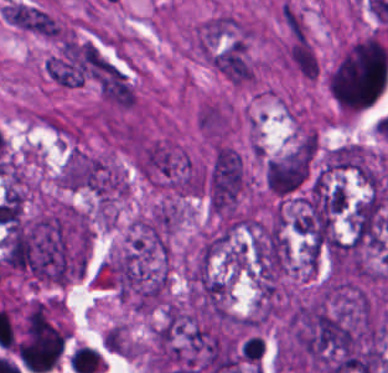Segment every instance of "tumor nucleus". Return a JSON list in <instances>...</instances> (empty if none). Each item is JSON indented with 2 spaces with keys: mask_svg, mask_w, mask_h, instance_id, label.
<instances>
[{
  "mask_svg": "<svg viewBox=\"0 0 388 373\" xmlns=\"http://www.w3.org/2000/svg\"><path fill=\"white\" fill-rule=\"evenodd\" d=\"M314 142H300L270 158L265 166V180L275 195H289L310 175Z\"/></svg>",
  "mask_w": 388,
  "mask_h": 373,
  "instance_id": "obj_1",
  "label": "tumor nucleus"
}]
</instances>
